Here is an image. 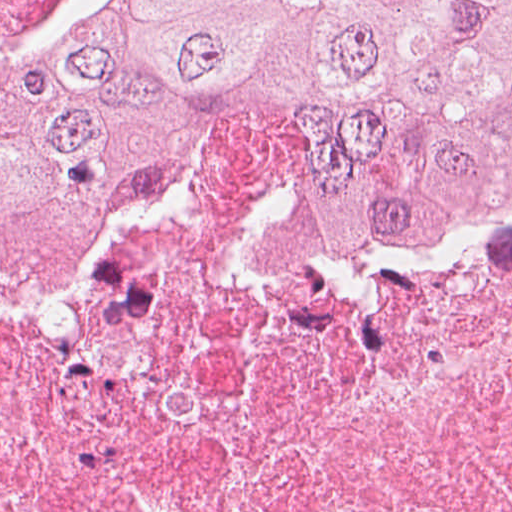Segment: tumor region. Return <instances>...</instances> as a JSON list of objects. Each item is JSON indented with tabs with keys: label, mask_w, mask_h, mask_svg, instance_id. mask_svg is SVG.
Returning <instances> with one entry per match:
<instances>
[{
	"label": "tumor region",
	"mask_w": 512,
	"mask_h": 512,
	"mask_svg": "<svg viewBox=\"0 0 512 512\" xmlns=\"http://www.w3.org/2000/svg\"><path fill=\"white\" fill-rule=\"evenodd\" d=\"M227 138L390 264L512 159V0H0V294L91 263Z\"/></svg>",
	"instance_id": "obj_1"
}]
</instances>
